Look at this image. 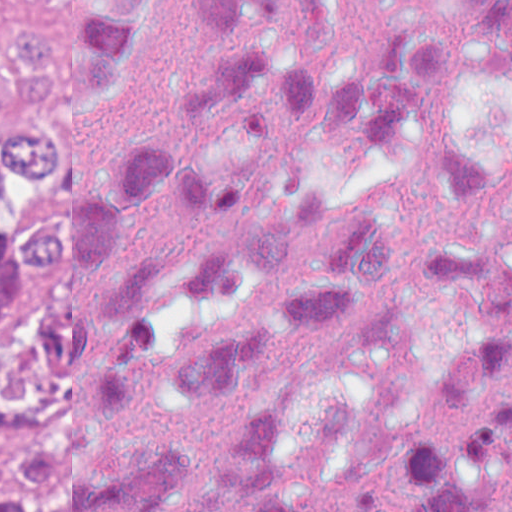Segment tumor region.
I'll list each match as a JSON object with an SVG mask.
<instances>
[{"label": "tumor region", "instance_id": "e687c5a6", "mask_svg": "<svg viewBox=\"0 0 512 512\" xmlns=\"http://www.w3.org/2000/svg\"><path fill=\"white\" fill-rule=\"evenodd\" d=\"M56 109H70V1H18L0 72V438L76 399L70 217L43 226L65 169ZM75 417L13 452L38 512L50 510ZM26 506L19 485L0 482V512Z\"/></svg>", "mask_w": 512, "mask_h": 512}]
</instances>
